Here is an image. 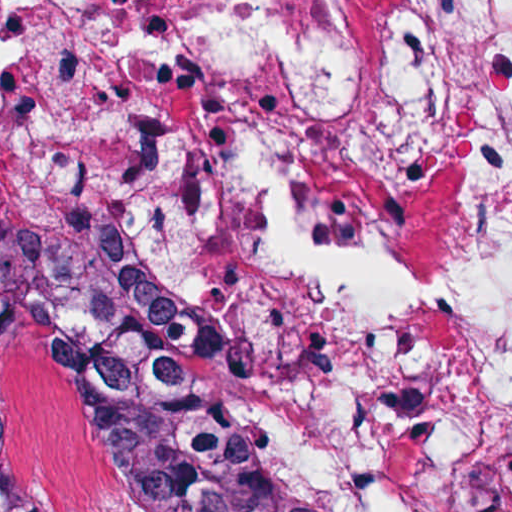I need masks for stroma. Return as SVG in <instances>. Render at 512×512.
<instances>
[{
	"instance_id": "stroma-1",
	"label": "stroma",
	"mask_w": 512,
	"mask_h": 512,
	"mask_svg": "<svg viewBox=\"0 0 512 512\" xmlns=\"http://www.w3.org/2000/svg\"><path fill=\"white\" fill-rule=\"evenodd\" d=\"M0 432L13 467L51 512H121L82 446L50 320L34 303L0 312Z\"/></svg>"
}]
</instances>
